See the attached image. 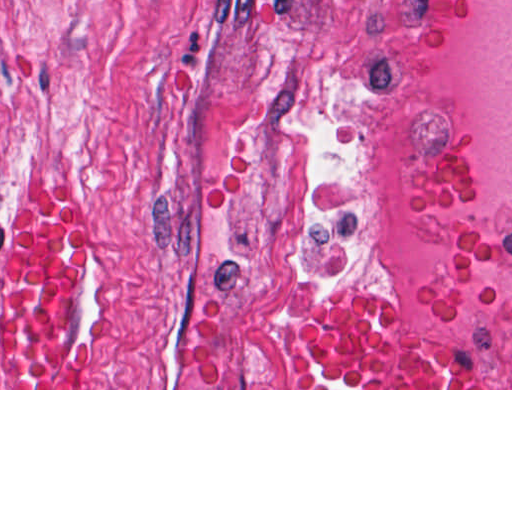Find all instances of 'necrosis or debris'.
<instances>
[{"label": "necrosis or debris", "instance_id": "obj_1", "mask_svg": "<svg viewBox=\"0 0 512 512\" xmlns=\"http://www.w3.org/2000/svg\"><path fill=\"white\" fill-rule=\"evenodd\" d=\"M386 261L426 326L512 388V0H360Z\"/></svg>", "mask_w": 512, "mask_h": 512}]
</instances>
